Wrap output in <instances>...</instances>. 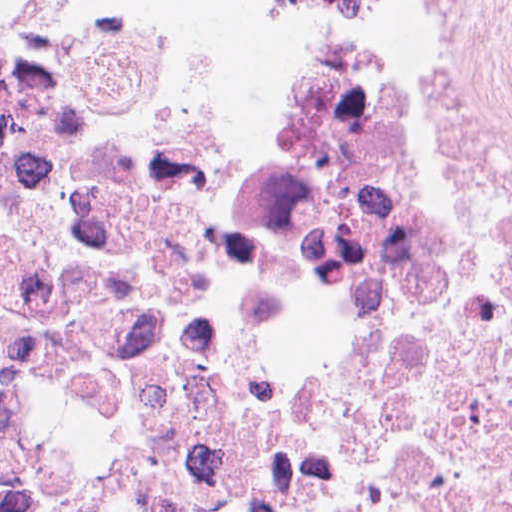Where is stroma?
<instances>
[{
  "label": "stroma",
  "mask_w": 512,
  "mask_h": 512,
  "mask_svg": "<svg viewBox=\"0 0 512 512\" xmlns=\"http://www.w3.org/2000/svg\"><path fill=\"white\" fill-rule=\"evenodd\" d=\"M123 18L205 27L223 65L227 93L277 74L255 0H103Z\"/></svg>",
  "instance_id": "35a3bbf8"
}]
</instances>
